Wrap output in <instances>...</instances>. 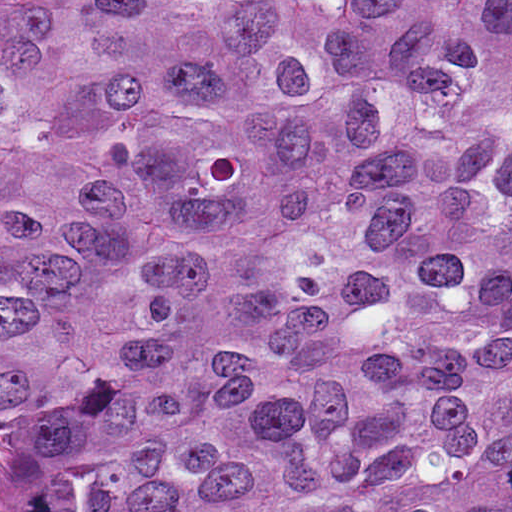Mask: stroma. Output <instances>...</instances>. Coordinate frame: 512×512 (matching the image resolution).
I'll return each mask as SVG.
<instances>
[{"mask_svg": "<svg viewBox=\"0 0 512 512\" xmlns=\"http://www.w3.org/2000/svg\"><path fill=\"white\" fill-rule=\"evenodd\" d=\"M0 512H21V502L0 470Z\"/></svg>", "mask_w": 512, "mask_h": 512, "instance_id": "stroma-1", "label": "stroma"}]
</instances>
